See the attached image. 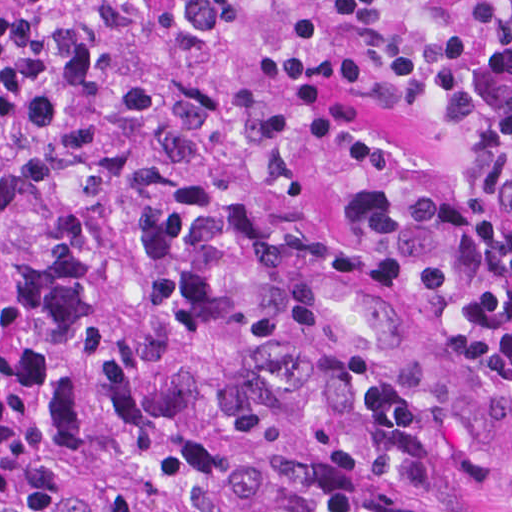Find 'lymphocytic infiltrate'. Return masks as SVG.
<instances>
[{
    "label": "lymphocytic infiltrate",
    "instance_id": "lymphocytic-infiltrate-1",
    "mask_svg": "<svg viewBox=\"0 0 512 512\" xmlns=\"http://www.w3.org/2000/svg\"><path fill=\"white\" fill-rule=\"evenodd\" d=\"M389 111L464 133L512 190V0H0L9 174L224 182Z\"/></svg>",
    "mask_w": 512,
    "mask_h": 512
}]
</instances>
